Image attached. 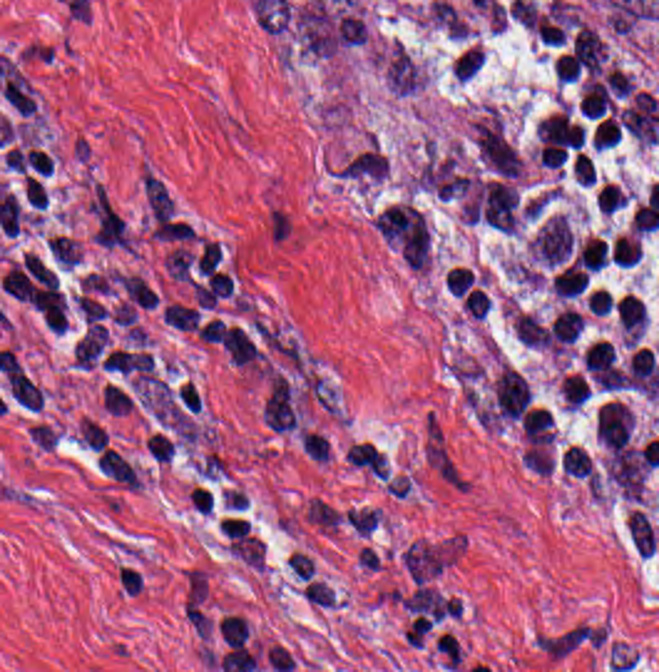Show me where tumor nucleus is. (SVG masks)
<instances>
[{"label":"tumor nucleus","mask_w":659,"mask_h":672,"mask_svg":"<svg viewBox=\"0 0 659 672\" xmlns=\"http://www.w3.org/2000/svg\"><path fill=\"white\" fill-rule=\"evenodd\" d=\"M377 62L397 94H416L426 79L423 66L401 41L390 39L378 48Z\"/></svg>","instance_id":"1"}]
</instances>
